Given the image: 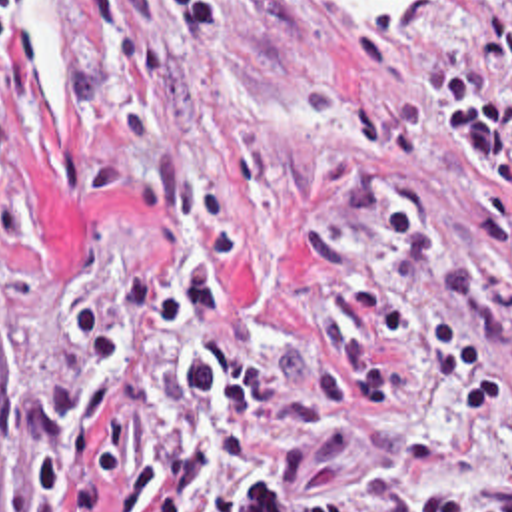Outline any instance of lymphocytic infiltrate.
Listing matches in <instances>:
<instances>
[{
  "label": "lymphocytic infiltrate",
  "instance_id": "lymphocytic-infiltrate-1",
  "mask_svg": "<svg viewBox=\"0 0 512 512\" xmlns=\"http://www.w3.org/2000/svg\"><path fill=\"white\" fill-rule=\"evenodd\" d=\"M181 1L185 59H207L231 43V13L223 0ZM486 15L476 57L512 83V0H458ZM15 25V3L0 0V47ZM430 99L442 101L438 129L462 139L486 183L474 216V238L492 258L506 256L512 226V107L498 103L486 81L460 65L430 71ZM139 197L161 222L199 232L197 252L177 270L173 294L157 272L127 278L115 324L97 306H77L61 322L77 358L57 386H9L11 422L31 434L33 500L61 504L71 472L97 434L95 456L67 512H187L211 450V480L195 512H350L346 500H279L269 470L251 442L257 422L295 428L299 462L332 466L346 456V424L324 408L350 416L376 404L400 378L392 354H414L450 376L458 398L476 414L494 412V374L482 350L438 312L408 318L364 272L328 212L303 236V252L324 274V290L307 310L295 338H277L245 324L225 294L235 256V228L219 220L209 195L183 177L173 157L159 153L139 181ZM191 322L223 324L239 342L271 362L215 358L187 348L175 366L177 446L171 460L145 462L113 486L115 458L131 440L129 418H109V402L153 360L167 336Z\"/></svg>",
  "mask_w": 512,
  "mask_h": 512
}]
</instances>
